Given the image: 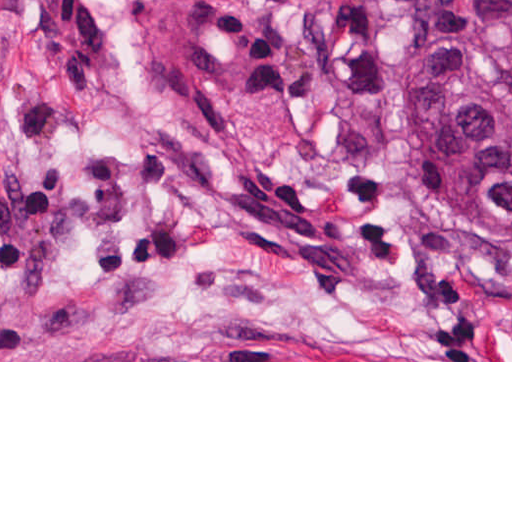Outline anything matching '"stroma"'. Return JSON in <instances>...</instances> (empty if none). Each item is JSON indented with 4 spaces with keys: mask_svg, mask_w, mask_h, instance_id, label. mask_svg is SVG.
<instances>
[{
    "mask_svg": "<svg viewBox=\"0 0 512 512\" xmlns=\"http://www.w3.org/2000/svg\"><path fill=\"white\" fill-rule=\"evenodd\" d=\"M379 0H199L115 59L0 0V362H512L397 195Z\"/></svg>",
    "mask_w": 512,
    "mask_h": 512,
    "instance_id": "stroma-1",
    "label": "stroma"
}]
</instances>
